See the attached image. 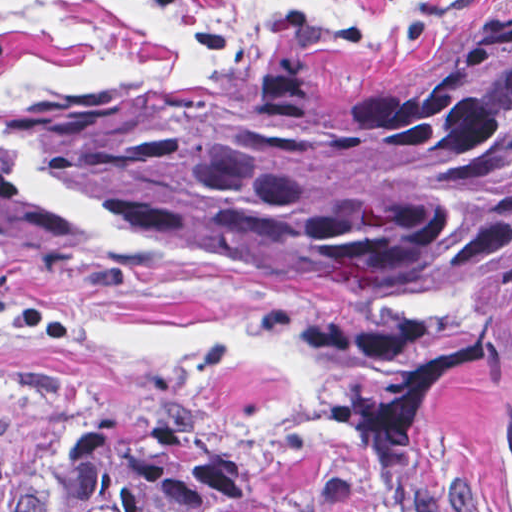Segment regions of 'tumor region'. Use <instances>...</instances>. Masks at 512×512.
I'll return each instance as SVG.
<instances>
[{
	"label": "tumor region",
	"mask_w": 512,
	"mask_h": 512,
	"mask_svg": "<svg viewBox=\"0 0 512 512\" xmlns=\"http://www.w3.org/2000/svg\"><path fill=\"white\" fill-rule=\"evenodd\" d=\"M0 247L304 292L286 319L382 458L498 391L512 510V17L346 78L230 58L79 98L0 97ZM337 465L228 488L111 431L33 512H341Z\"/></svg>",
	"instance_id": "tumor-region-1"
}]
</instances>
